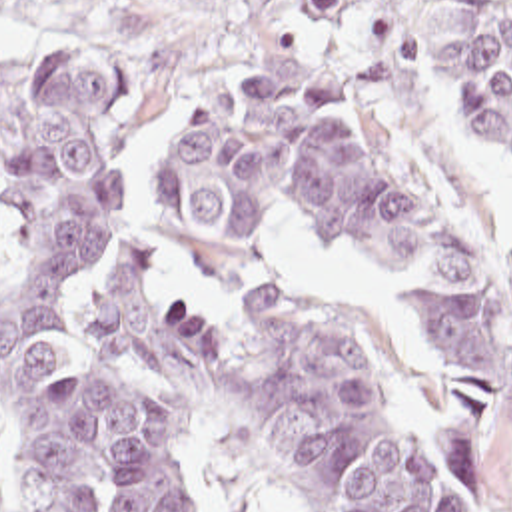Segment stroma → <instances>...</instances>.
Here are the masks:
<instances>
[{"instance_id":"obj_1","label":"stroma","mask_w":512,"mask_h":512,"mask_svg":"<svg viewBox=\"0 0 512 512\" xmlns=\"http://www.w3.org/2000/svg\"><path fill=\"white\" fill-rule=\"evenodd\" d=\"M447 2L413 0V76L390 98H352L330 56L278 24L260 0H12L0 6V60L60 58L118 70L116 200L74 266L80 320L130 240L162 244L156 172L180 118L198 98L276 76L310 80L364 106L394 144L465 212L512 290V148L441 124L429 64V20ZM270 284L284 302L358 342L388 408L423 454L455 512H512V452L443 368L419 328L400 276L340 254L306 214L286 208L260 224ZM10 242L0 228V280ZM180 428L206 509L308 512L278 484L226 400L204 406L148 384ZM0 512H30L12 426L0 414Z\"/></svg>"}]
</instances>
